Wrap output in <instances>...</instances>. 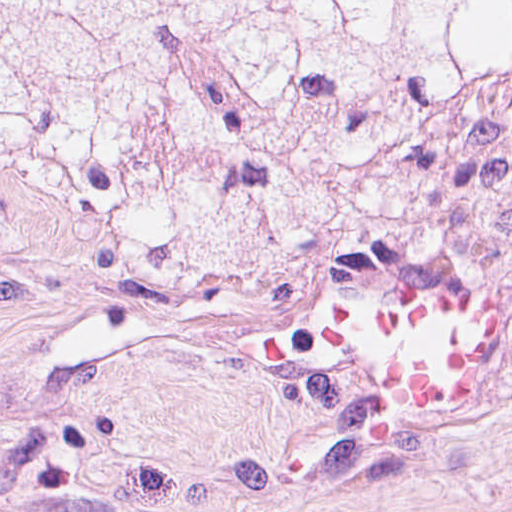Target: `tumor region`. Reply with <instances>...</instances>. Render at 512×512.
<instances>
[{
	"instance_id": "e687c5a6",
	"label": "tumor region",
	"mask_w": 512,
	"mask_h": 512,
	"mask_svg": "<svg viewBox=\"0 0 512 512\" xmlns=\"http://www.w3.org/2000/svg\"><path fill=\"white\" fill-rule=\"evenodd\" d=\"M448 154L512 241V0H0V227L75 208L254 270L290 206L363 219Z\"/></svg>"
}]
</instances>
